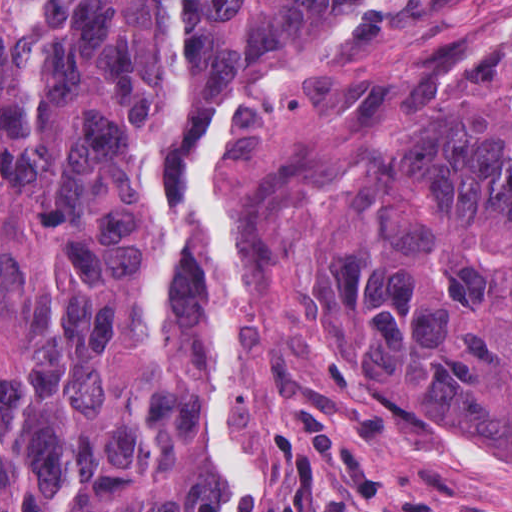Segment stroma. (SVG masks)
<instances>
[{"label":"stroma","mask_w":512,"mask_h":512,"mask_svg":"<svg viewBox=\"0 0 512 512\" xmlns=\"http://www.w3.org/2000/svg\"><path fill=\"white\" fill-rule=\"evenodd\" d=\"M510 65L512 0H347L206 104L188 165L217 252L191 368L240 455L223 512H512V461L421 410L329 397L306 345L369 105Z\"/></svg>","instance_id":"35a3bbf8"}]
</instances>
